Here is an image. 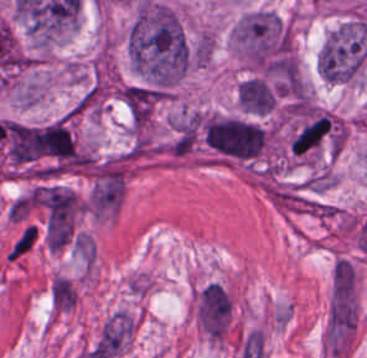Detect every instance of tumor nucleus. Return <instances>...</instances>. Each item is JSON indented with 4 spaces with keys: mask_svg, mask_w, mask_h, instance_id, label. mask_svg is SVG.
<instances>
[{
    "mask_svg": "<svg viewBox=\"0 0 367 358\" xmlns=\"http://www.w3.org/2000/svg\"><path fill=\"white\" fill-rule=\"evenodd\" d=\"M128 60L140 79L177 80L187 71L190 46L175 12L140 0L126 32Z\"/></svg>",
    "mask_w": 367,
    "mask_h": 358,
    "instance_id": "tumor-nucleus-1",
    "label": "tumor nucleus"
},
{
    "mask_svg": "<svg viewBox=\"0 0 367 358\" xmlns=\"http://www.w3.org/2000/svg\"><path fill=\"white\" fill-rule=\"evenodd\" d=\"M366 55L363 21H344L326 35L318 55V70L328 82L345 83L357 78Z\"/></svg>",
    "mask_w": 367,
    "mask_h": 358,
    "instance_id": "tumor-nucleus-2",
    "label": "tumor nucleus"
},
{
    "mask_svg": "<svg viewBox=\"0 0 367 358\" xmlns=\"http://www.w3.org/2000/svg\"><path fill=\"white\" fill-rule=\"evenodd\" d=\"M36 242V231L34 223H26L22 226L13 240L5 261L17 262L30 252Z\"/></svg>",
    "mask_w": 367,
    "mask_h": 358,
    "instance_id": "tumor-nucleus-6",
    "label": "tumor nucleus"
},
{
    "mask_svg": "<svg viewBox=\"0 0 367 358\" xmlns=\"http://www.w3.org/2000/svg\"><path fill=\"white\" fill-rule=\"evenodd\" d=\"M209 146L225 160L247 161L259 155L268 138L267 129L254 119L226 113L204 117Z\"/></svg>",
    "mask_w": 367,
    "mask_h": 358,
    "instance_id": "tumor-nucleus-3",
    "label": "tumor nucleus"
},
{
    "mask_svg": "<svg viewBox=\"0 0 367 358\" xmlns=\"http://www.w3.org/2000/svg\"><path fill=\"white\" fill-rule=\"evenodd\" d=\"M333 127L334 120L327 112L314 110L305 114L288 140L293 155H313L331 135Z\"/></svg>",
    "mask_w": 367,
    "mask_h": 358,
    "instance_id": "tumor-nucleus-4",
    "label": "tumor nucleus"
},
{
    "mask_svg": "<svg viewBox=\"0 0 367 358\" xmlns=\"http://www.w3.org/2000/svg\"><path fill=\"white\" fill-rule=\"evenodd\" d=\"M240 107L252 115H265L272 111L278 100V90L262 76H248L236 88Z\"/></svg>",
    "mask_w": 367,
    "mask_h": 358,
    "instance_id": "tumor-nucleus-5",
    "label": "tumor nucleus"
}]
</instances>
